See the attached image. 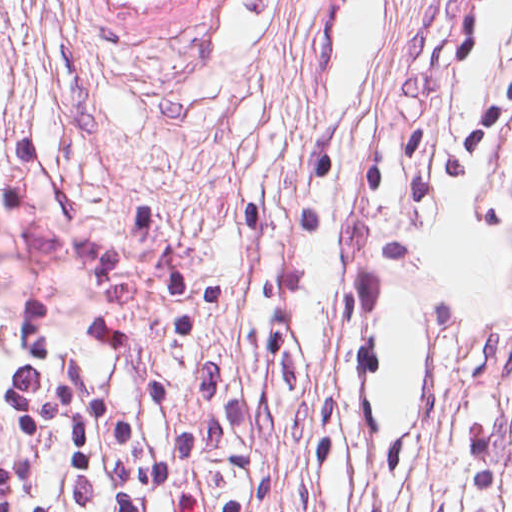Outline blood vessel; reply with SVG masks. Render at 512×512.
Segmentation results:
<instances>
[{"instance_id":"obj_1","label":"blood vessel","mask_w":512,"mask_h":512,"mask_svg":"<svg viewBox=\"0 0 512 512\" xmlns=\"http://www.w3.org/2000/svg\"><path fill=\"white\" fill-rule=\"evenodd\" d=\"M98 32L124 52L165 53L194 37L223 0H80Z\"/></svg>"}]
</instances>
